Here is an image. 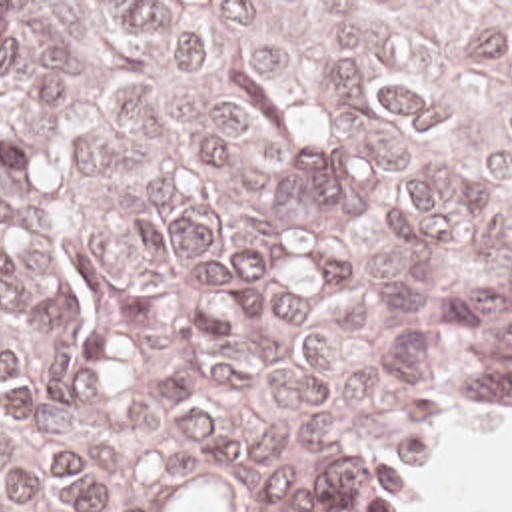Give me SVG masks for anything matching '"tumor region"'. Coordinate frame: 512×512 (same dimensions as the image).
<instances>
[{
	"mask_svg": "<svg viewBox=\"0 0 512 512\" xmlns=\"http://www.w3.org/2000/svg\"><path fill=\"white\" fill-rule=\"evenodd\" d=\"M512 403V2H0V512H368Z\"/></svg>",
	"mask_w": 512,
	"mask_h": 512,
	"instance_id": "1",
	"label": "tumor region"
}]
</instances>
